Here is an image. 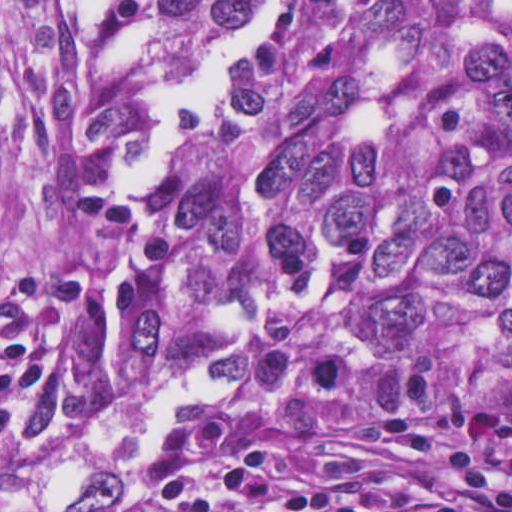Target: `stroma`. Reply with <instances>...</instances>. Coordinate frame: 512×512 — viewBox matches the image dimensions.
<instances>
[{"label": "stroma", "mask_w": 512, "mask_h": 512, "mask_svg": "<svg viewBox=\"0 0 512 512\" xmlns=\"http://www.w3.org/2000/svg\"><path fill=\"white\" fill-rule=\"evenodd\" d=\"M298 359L334 352L347 363V381L321 408L283 410L258 421L236 438L222 473L248 466L265 444L286 437L312 436L329 443L342 459L343 480L369 491H406L434 501L444 512H504L478 503L389 442L383 419L405 412L495 414L508 411H404L369 413L361 409L365 356L358 307L344 293L320 286L301 309L294 332ZM297 379L286 396L295 391ZM280 397V398H281ZM205 416V415H204ZM198 417L194 421L200 419ZM151 496L133 482L131 491L105 512H137ZM0 512H1V0H0Z\"/></svg>", "instance_id": "35a3bbf8"}]
</instances>
